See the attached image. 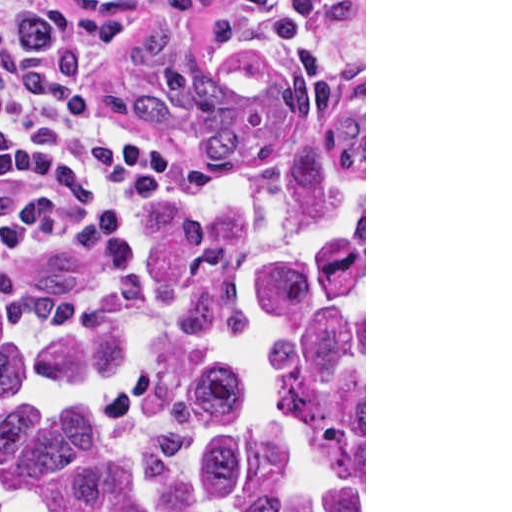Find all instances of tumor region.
<instances>
[{
    "label": "tumor region",
    "instance_id": "e687c5a6",
    "mask_svg": "<svg viewBox=\"0 0 512 512\" xmlns=\"http://www.w3.org/2000/svg\"><path fill=\"white\" fill-rule=\"evenodd\" d=\"M202 185L0 265V512H364V104L223 0H80Z\"/></svg>",
    "mask_w": 512,
    "mask_h": 512
}]
</instances>
